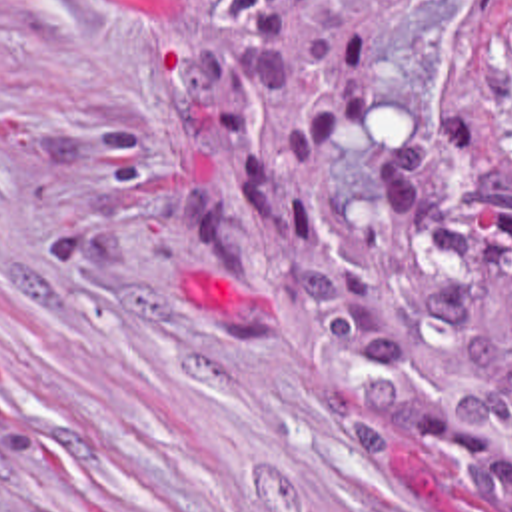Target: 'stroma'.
Listing matches in <instances>:
<instances>
[{"mask_svg":"<svg viewBox=\"0 0 512 512\" xmlns=\"http://www.w3.org/2000/svg\"><path fill=\"white\" fill-rule=\"evenodd\" d=\"M494 0L392 17L360 132L324 142L310 242L372 228L440 106L506 130ZM394 368L244 232L230 132L142 0H0V512H498L354 410Z\"/></svg>","mask_w":512,"mask_h":512,"instance_id":"obj_1","label":"stroma"}]
</instances>
